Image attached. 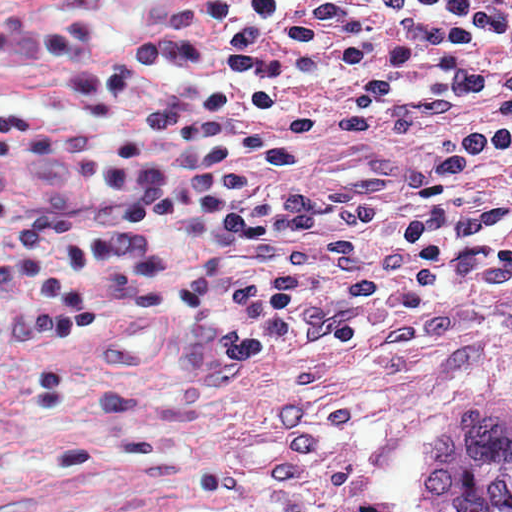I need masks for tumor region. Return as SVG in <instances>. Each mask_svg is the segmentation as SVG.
I'll return each mask as SVG.
<instances>
[{
  "instance_id": "tumor-region-1",
  "label": "tumor region",
  "mask_w": 512,
  "mask_h": 512,
  "mask_svg": "<svg viewBox=\"0 0 512 512\" xmlns=\"http://www.w3.org/2000/svg\"><path fill=\"white\" fill-rule=\"evenodd\" d=\"M428 512H512V396L458 402L422 469Z\"/></svg>"
}]
</instances>
